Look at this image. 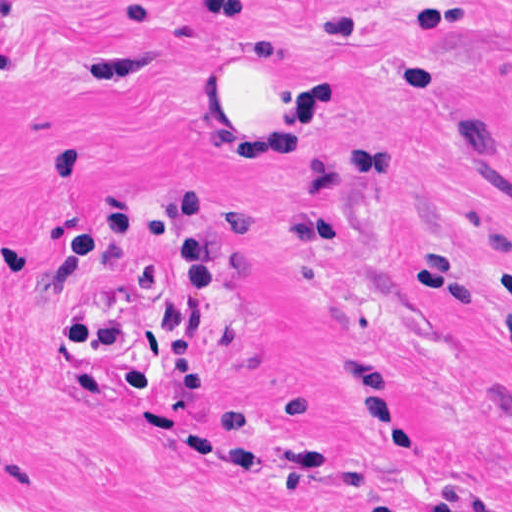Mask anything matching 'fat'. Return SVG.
<instances>
[{"mask_svg": "<svg viewBox=\"0 0 512 512\" xmlns=\"http://www.w3.org/2000/svg\"><path fill=\"white\" fill-rule=\"evenodd\" d=\"M320 31L213 60L237 90V156L300 160L320 145Z\"/></svg>", "mask_w": 512, "mask_h": 512, "instance_id": "53f6f03d", "label": "fat"}]
</instances>
